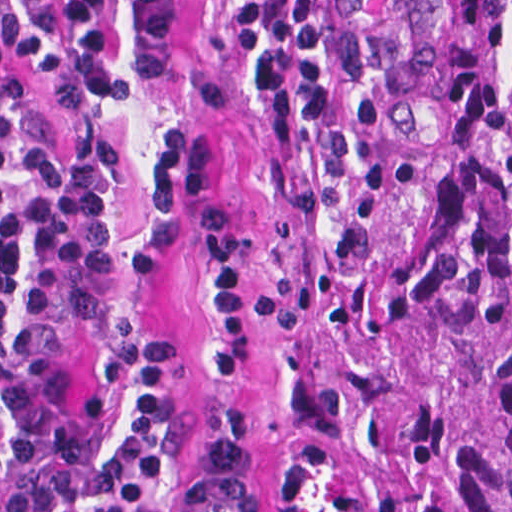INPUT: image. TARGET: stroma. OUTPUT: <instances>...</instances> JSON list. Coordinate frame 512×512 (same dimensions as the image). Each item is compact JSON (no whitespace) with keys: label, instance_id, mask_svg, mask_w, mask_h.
Segmentation results:
<instances>
[{"label":"stroma","instance_id":"stroma-1","mask_svg":"<svg viewBox=\"0 0 512 512\" xmlns=\"http://www.w3.org/2000/svg\"><path fill=\"white\" fill-rule=\"evenodd\" d=\"M287 0H194L186 43L169 73L145 77L129 0H110V38L127 95L59 81L16 48L0 0V55L35 92L43 136L55 153L103 129L114 143V200L123 225V282L135 311L174 362V399L185 426L213 438V460L177 512H332L344 426L337 374L355 344L389 174L373 104L349 66L341 0H330L325 62L343 106V137L285 156L249 91L243 68L273 46ZM206 136L213 191L250 229L246 299L250 370L211 376L198 353L216 296L194 194L179 195L183 238L152 270L133 274L126 251L155 210L151 157L167 123ZM112 512H123L1 265Z\"/></svg>","mask_w":512,"mask_h":512}]
</instances>
